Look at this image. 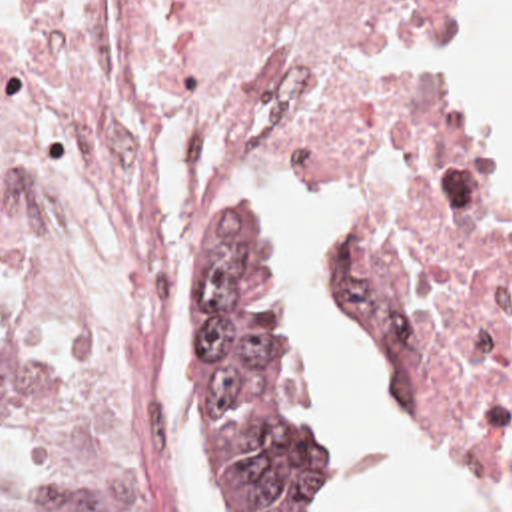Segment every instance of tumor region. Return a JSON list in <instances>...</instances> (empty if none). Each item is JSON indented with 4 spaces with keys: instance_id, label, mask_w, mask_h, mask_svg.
<instances>
[{
    "instance_id": "obj_1",
    "label": "tumor region",
    "mask_w": 512,
    "mask_h": 512,
    "mask_svg": "<svg viewBox=\"0 0 512 512\" xmlns=\"http://www.w3.org/2000/svg\"><path fill=\"white\" fill-rule=\"evenodd\" d=\"M287 262L279 236L225 218L205 272V322L197 362L201 405L255 512H297L323 459L319 435L291 417L309 362L289 280L277 308L261 292ZM31 350L0 312V417L18 401ZM0 512H103L85 493L2 457Z\"/></svg>"
}]
</instances>
